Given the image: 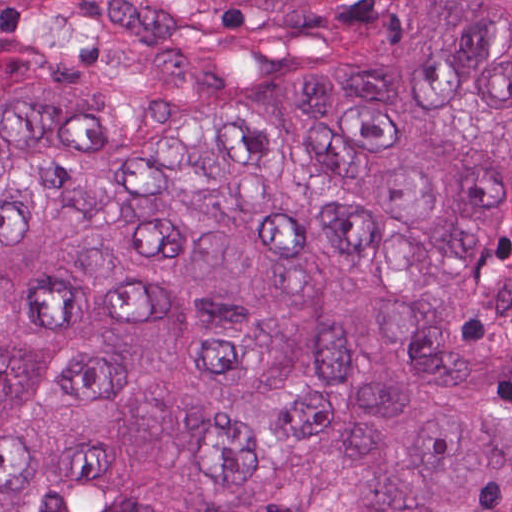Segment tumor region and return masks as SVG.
I'll return each mask as SVG.
<instances>
[{
    "instance_id": "e687c5a6",
    "label": "tumor region",
    "mask_w": 512,
    "mask_h": 512,
    "mask_svg": "<svg viewBox=\"0 0 512 512\" xmlns=\"http://www.w3.org/2000/svg\"><path fill=\"white\" fill-rule=\"evenodd\" d=\"M0 512H512V0H0Z\"/></svg>"
}]
</instances>
